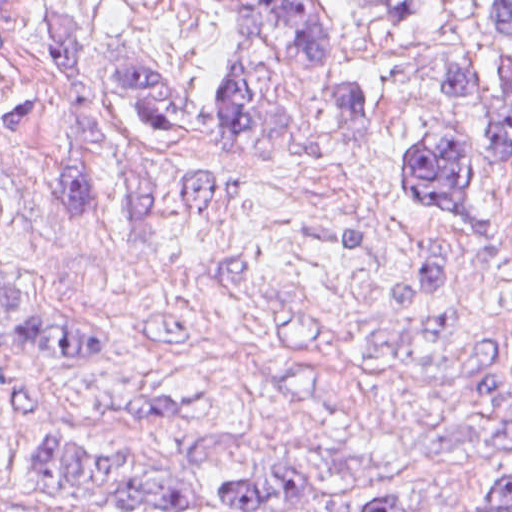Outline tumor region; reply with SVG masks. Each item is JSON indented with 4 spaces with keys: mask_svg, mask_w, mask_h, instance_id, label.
Instances as JSON below:
<instances>
[{
    "mask_svg": "<svg viewBox=\"0 0 512 512\" xmlns=\"http://www.w3.org/2000/svg\"><path fill=\"white\" fill-rule=\"evenodd\" d=\"M377 19H417L436 0H344ZM487 28L512 42V0H473ZM225 34L243 61V82L217 97L179 64L156 52L126 59L63 0L48 12L56 67L50 84H0V117L19 126H50L37 184L41 202L66 220H205L253 192L223 174L165 172L122 149L97 118L91 94L130 104L156 138L270 155L324 149L329 134L280 106L304 70L328 73L325 106L342 129L379 131L371 90L356 81L341 54L338 22L324 0H214ZM486 125L512 168V62H466L437 81ZM399 184L409 202L479 227V199L465 156L438 140L407 149ZM132 357L34 315L23 289L5 200L0 195V388L18 366L38 359L81 361ZM210 393L140 398L124 405L141 419H192L226 411L249 394L219 378ZM236 440L215 436L171 464L117 465L49 443L40 466L42 491L114 502L142 512H403L415 480L378 460L351 456L289 434L276 425L267 452L236 481L200 475L225 460ZM458 512H512V475L478 490Z\"/></svg>",
    "mask_w": 512,
    "mask_h": 512,
    "instance_id": "tumor-region-1",
    "label": "tumor region"
}]
</instances>
